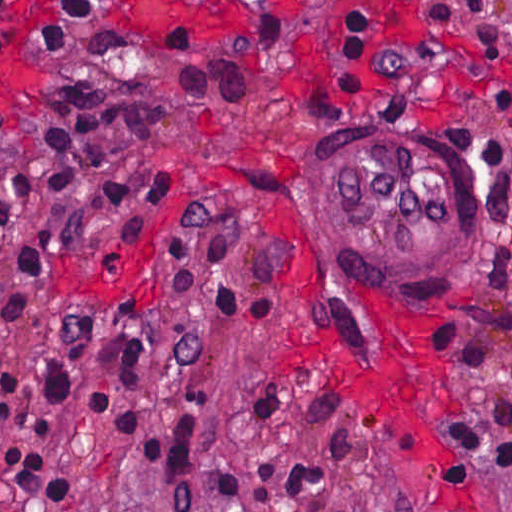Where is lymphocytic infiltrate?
Returning a JSON list of instances; mask_svg holds the SVG:
<instances>
[{
	"label": "lymphocytic infiltrate",
	"instance_id": "1",
	"mask_svg": "<svg viewBox=\"0 0 512 512\" xmlns=\"http://www.w3.org/2000/svg\"><path fill=\"white\" fill-rule=\"evenodd\" d=\"M0 0V54L12 48L79 52L147 69L157 84L123 79L117 102H96L67 115L0 129V140L20 147L0 188V331L34 316L47 294V262L58 236L78 237L98 220L132 215L178 194L172 173L110 177L101 162L141 142L162 126L177 102L216 107L256 91L270 60L287 50L288 28L271 20L237 30L218 44L196 26L133 33L107 23L88 0H55L38 29L17 31L11 3ZM345 90H364L367 36L358 14L348 13L332 60ZM197 103V104H191ZM95 310L81 315L67 351L41 370V392L32 414L34 435H51L95 353ZM507 316L461 312L432 333L441 355L461 370L465 393L450 423V448L467 393L490 364ZM114 371L122 389L140 390L138 363L147 361L146 327L128 323L113 339ZM103 391L89 393V418L101 429ZM13 371L0 353V438L12 419ZM195 425L179 418L167 431H147L129 407L118 405L110 431L125 435L141 453ZM46 458L24 446L0 455V480L12 498L35 511L68 499L70 478L52 476ZM445 462L438 468L443 471Z\"/></svg>",
	"mask_w": 512,
	"mask_h": 512
}]
</instances>
